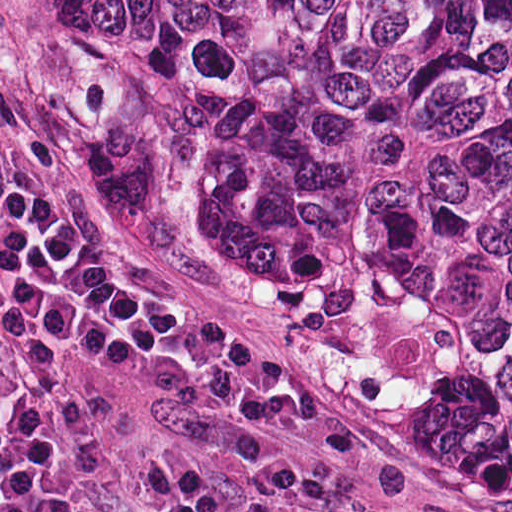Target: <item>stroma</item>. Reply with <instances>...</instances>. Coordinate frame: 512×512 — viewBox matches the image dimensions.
Wrapping results in <instances>:
<instances>
[{
    "label": "stroma",
    "instance_id": "obj_1",
    "mask_svg": "<svg viewBox=\"0 0 512 512\" xmlns=\"http://www.w3.org/2000/svg\"><path fill=\"white\" fill-rule=\"evenodd\" d=\"M0 69L70 210L166 282L196 335L235 351L256 388L322 419L292 424L220 409L166 410L164 396L85 359L48 398L77 457L59 468L106 512H177L167 450L201 444L238 512H512V493L445 494L337 399L293 348L241 272L209 242L142 201L98 190L83 152L113 123L100 89L52 26V0H0Z\"/></svg>",
    "mask_w": 512,
    "mask_h": 512
}]
</instances>
